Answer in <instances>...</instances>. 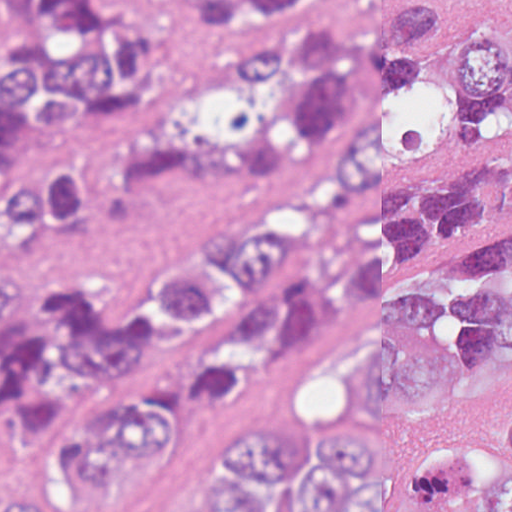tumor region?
<instances>
[{"label":"tumor region","mask_w":512,"mask_h":512,"mask_svg":"<svg viewBox=\"0 0 512 512\" xmlns=\"http://www.w3.org/2000/svg\"><path fill=\"white\" fill-rule=\"evenodd\" d=\"M512 99V1H428L414 94L396 134L340 183L315 217L285 216L191 264L136 317L81 286L0 298V415L13 443L62 432L99 382L130 374L212 333L265 269L299 252L302 280L228 315L183 376V396L220 402L270 384L279 368L367 309L372 335L355 385L378 407L414 412L512 362V221L430 262H399L473 221L512 217V162L444 170L350 219L361 191ZM157 403L108 397L60 436L57 452L90 479L154 452ZM80 486V485H78ZM14 496L8 512H43ZM203 512H512V381L485 439H439L400 464L351 433L312 420H233L209 455Z\"/></svg>","instance_id":"obj_1"}]
</instances>
